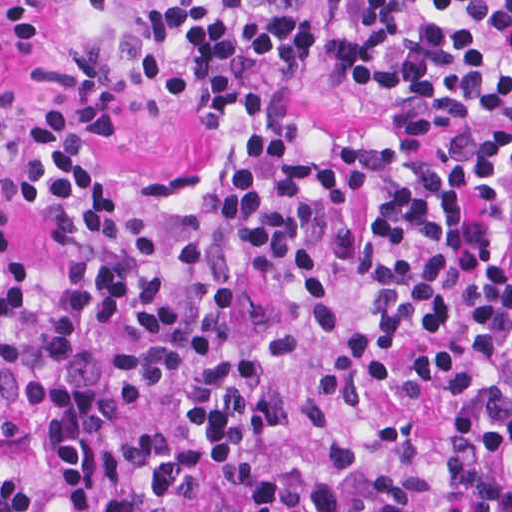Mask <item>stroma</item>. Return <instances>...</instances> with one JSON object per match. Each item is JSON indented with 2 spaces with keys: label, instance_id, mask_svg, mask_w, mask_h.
Instances as JSON below:
<instances>
[{
  "label": "stroma",
  "instance_id": "1",
  "mask_svg": "<svg viewBox=\"0 0 512 512\" xmlns=\"http://www.w3.org/2000/svg\"><path fill=\"white\" fill-rule=\"evenodd\" d=\"M348 0H311L317 33V65L305 85L294 89L274 110L260 118H234L215 128L200 109H163L137 132H103L94 128L64 96L51 93L40 76L44 64L64 57L88 33L101 29L104 17L86 8L71 11L62 41L42 50L17 43L0 4V65L7 74L12 143L0 155V306L15 276L31 262L41 272V306L12 336H26L46 326L62 297L68 276L66 259L50 240L52 216L22 196L29 163V120L38 111L62 113L82 127L87 161L105 173L117 206L142 215L153 239L166 255L163 291L176 313L172 338L175 374L164 393L147 409L132 407L110 376V360L129 347V338L109 326L99 329L77 370L118 413L116 435H143L166 428L176 433V448L187 441L185 409L179 393L189 364L187 317L193 301V278L180 260L186 231L206 222L241 173V153L248 136L274 117H300L325 135L365 131L383 135L396 106L391 88H363L328 64V43ZM503 256L512 269V194L497 220ZM132 465L122 487L136 512H223L219 488L200 485L184 499L168 501L154 489L163 457Z\"/></svg>",
  "mask_w": 512,
  "mask_h": 512
}]
</instances>
